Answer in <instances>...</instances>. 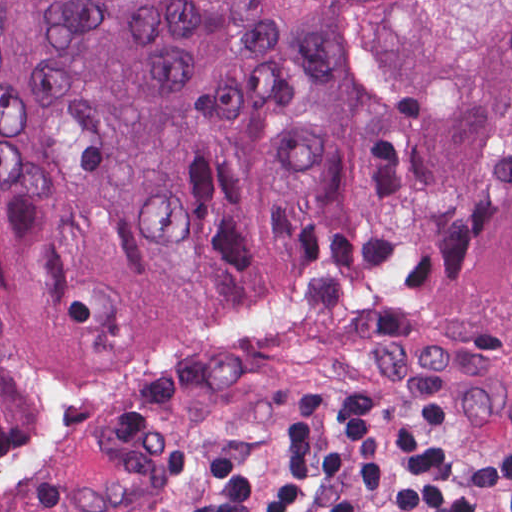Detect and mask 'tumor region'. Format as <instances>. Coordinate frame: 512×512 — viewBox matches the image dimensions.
Returning <instances> with one entry per match:
<instances>
[{
    "label": "tumor region",
    "mask_w": 512,
    "mask_h": 512,
    "mask_svg": "<svg viewBox=\"0 0 512 512\" xmlns=\"http://www.w3.org/2000/svg\"><path fill=\"white\" fill-rule=\"evenodd\" d=\"M332 1L0 0V449L34 374L252 310L512 341V89L385 101Z\"/></svg>",
    "instance_id": "obj_1"
}]
</instances>
